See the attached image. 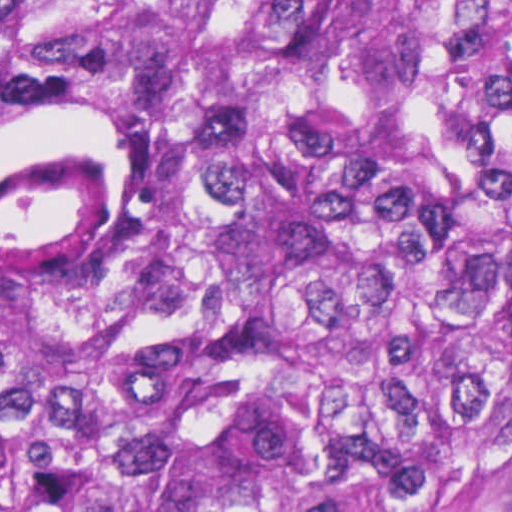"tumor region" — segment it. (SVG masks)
I'll use <instances>...</instances> for the list:
<instances>
[{
  "instance_id": "obj_1",
  "label": "tumor region",
  "mask_w": 512,
  "mask_h": 512,
  "mask_svg": "<svg viewBox=\"0 0 512 512\" xmlns=\"http://www.w3.org/2000/svg\"><path fill=\"white\" fill-rule=\"evenodd\" d=\"M117 168L0 272V512H512V0H0V163Z\"/></svg>"
}]
</instances>
